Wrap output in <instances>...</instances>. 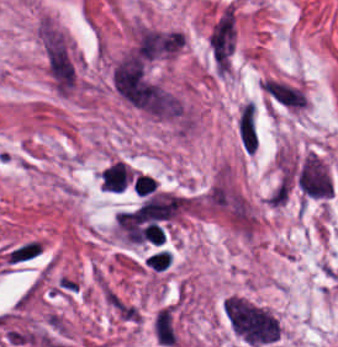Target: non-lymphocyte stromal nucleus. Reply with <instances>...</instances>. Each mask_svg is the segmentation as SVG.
<instances>
[{
    "label": "non-lymphocyte stromal nucleus",
    "mask_w": 338,
    "mask_h": 347,
    "mask_svg": "<svg viewBox=\"0 0 338 347\" xmlns=\"http://www.w3.org/2000/svg\"><path fill=\"white\" fill-rule=\"evenodd\" d=\"M43 46L47 70L58 92L66 93L74 83V64L58 29L44 26Z\"/></svg>",
    "instance_id": "dd21d789"
},
{
    "label": "non-lymphocyte stromal nucleus",
    "mask_w": 338,
    "mask_h": 347,
    "mask_svg": "<svg viewBox=\"0 0 338 347\" xmlns=\"http://www.w3.org/2000/svg\"><path fill=\"white\" fill-rule=\"evenodd\" d=\"M295 181L306 198L328 199L332 192L329 170L317 153H309L301 161Z\"/></svg>",
    "instance_id": "a72fc3eb"
},
{
    "label": "non-lymphocyte stromal nucleus",
    "mask_w": 338,
    "mask_h": 347,
    "mask_svg": "<svg viewBox=\"0 0 338 347\" xmlns=\"http://www.w3.org/2000/svg\"><path fill=\"white\" fill-rule=\"evenodd\" d=\"M233 45V22L229 13H222L211 29L210 48L213 59H227Z\"/></svg>",
    "instance_id": "3746e769"
},
{
    "label": "non-lymphocyte stromal nucleus",
    "mask_w": 338,
    "mask_h": 347,
    "mask_svg": "<svg viewBox=\"0 0 338 347\" xmlns=\"http://www.w3.org/2000/svg\"><path fill=\"white\" fill-rule=\"evenodd\" d=\"M42 249L40 239L30 237L11 245L2 252L0 257L6 265H19L33 260Z\"/></svg>",
    "instance_id": "fc2b8d12"
},
{
    "label": "non-lymphocyte stromal nucleus",
    "mask_w": 338,
    "mask_h": 347,
    "mask_svg": "<svg viewBox=\"0 0 338 347\" xmlns=\"http://www.w3.org/2000/svg\"><path fill=\"white\" fill-rule=\"evenodd\" d=\"M156 342L164 347L174 344L176 338L174 311L171 306L158 309L152 323Z\"/></svg>",
    "instance_id": "81446118"
},
{
    "label": "non-lymphocyte stromal nucleus",
    "mask_w": 338,
    "mask_h": 347,
    "mask_svg": "<svg viewBox=\"0 0 338 347\" xmlns=\"http://www.w3.org/2000/svg\"><path fill=\"white\" fill-rule=\"evenodd\" d=\"M259 84L272 97L287 106L298 107L303 103L302 91L285 82L264 78L259 80Z\"/></svg>",
    "instance_id": "7c5642bf"
},
{
    "label": "non-lymphocyte stromal nucleus",
    "mask_w": 338,
    "mask_h": 347,
    "mask_svg": "<svg viewBox=\"0 0 338 347\" xmlns=\"http://www.w3.org/2000/svg\"><path fill=\"white\" fill-rule=\"evenodd\" d=\"M238 137L247 151H254L258 143V133L254 111L245 103L238 115Z\"/></svg>",
    "instance_id": "9d01c50a"
},
{
    "label": "non-lymphocyte stromal nucleus",
    "mask_w": 338,
    "mask_h": 347,
    "mask_svg": "<svg viewBox=\"0 0 338 347\" xmlns=\"http://www.w3.org/2000/svg\"><path fill=\"white\" fill-rule=\"evenodd\" d=\"M291 187V175L286 170L281 174L268 199L271 206H283Z\"/></svg>",
    "instance_id": "2ac0efb1"
}]
</instances>
